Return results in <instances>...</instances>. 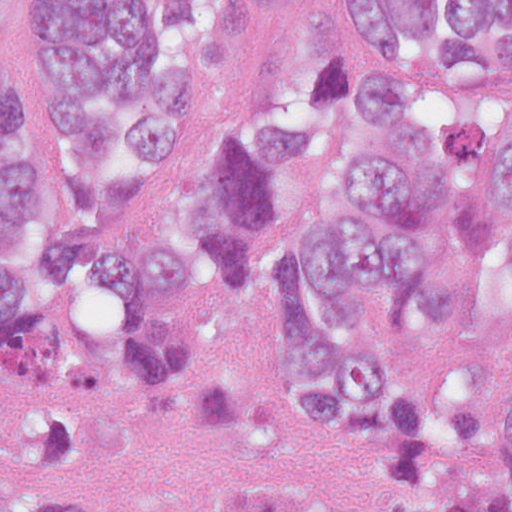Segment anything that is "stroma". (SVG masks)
Listing matches in <instances>:
<instances>
[{
    "label": "stroma",
    "instance_id": "obj_1",
    "mask_svg": "<svg viewBox=\"0 0 512 512\" xmlns=\"http://www.w3.org/2000/svg\"><path fill=\"white\" fill-rule=\"evenodd\" d=\"M5 29L45 108L60 191L71 209L56 160V92L32 34V0H6ZM463 103L471 121L495 137H512V71L467 81ZM47 311L84 334L142 323L117 295L99 291H71ZM168 325L199 331L206 352L262 390V415L250 431H172L115 415L92 450L54 466H9L0 446V489L62 488L84 500V512H172L194 489L299 481L337 493L356 485L389 400H374L363 420L344 424L296 415L285 400L297 341L288 278L269 271L254 283L213 279Z\"/></svg>",
    "mask_w": 512,
    "mask_h": 512
}]
</instances>
